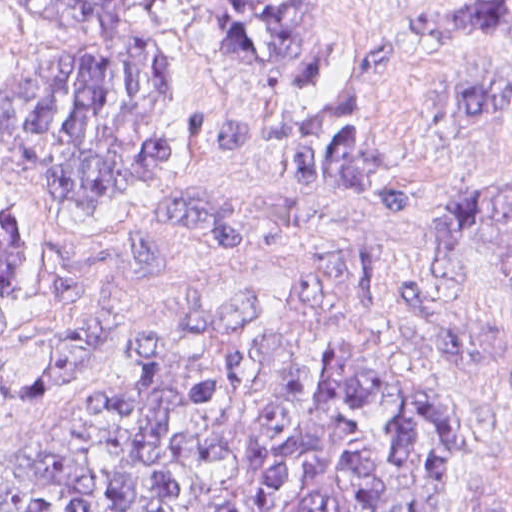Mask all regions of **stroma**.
Instances as JSON below:
<instances>
[{"label": "stroma", "instance_id": "stroma-1", "mask_svg": "<svg viewBox=\"0 0 512 512\" xmlns=\"http://www.w3.org/2000/svg\"><path fill=\"white\" fill-rule=\"evenodd\" d=\"M16 1H171L156 11L154 28L170 53L182 115L169 134L171 164L134 185L114 221L66 216L42 177L0 150V210L14 205L35 233L25 261L32 283L0 306V346L47 332L81 308L121 312L135 328L134 351L102 389L14 416L0 427V449L109 393L168 333L225 327L349 273L390 272L378 331L401 366L452 403L456 421L440 512H498L512 501V282L449 273L441 266L446 244L431 236L434 205L512 177V101L500 117H455L449 105L459 85L512 80V38L428 40L412 30L421 10L512 0H0V81L79 40L78 31L42 23ZM177 1H328L347 63L312 95H272L219 60L222 35ZM386 38L400 45L362 134L390 155L384 178L415 197L412 212L285 182L277 146L221 153L183 136L192 110L318 118Z\"/></svg>", "mask_w": 512, "mask_h": 512}]
</instances>
